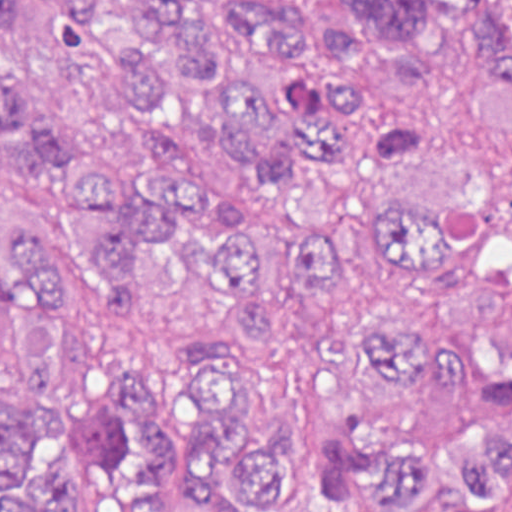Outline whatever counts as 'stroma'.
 <instances>
[{"instance_id": "35a3bbf8", "label": "stroma", "mask_w": 512, "mask_h": 512, "mask_svg": "<svg viewBox=\"0 0 512 512\" xmlns=\"http://www.w3.org/2000/svg\"><path fill=\"white\" fill-rule=\"evenodd\" d=\"M299 1L308 9L312 53L327 64H346L365 75V101L346 116H327L341 122L354 139L346 163L308 155L289 194L264 199L194 108L178 123V149L190 171L205 182H230L249 190V216L273 253V278L265 296L247 300H285L298 287V227L305 211L341 179L357 173L402 115L389 81L363 58L342 53L320 31L319 11L334 0ZM200 503L189 462L170 466V512H199ZM64 512L117 511L90 477L72 488Z\"/></svg>"}]
</instances>
